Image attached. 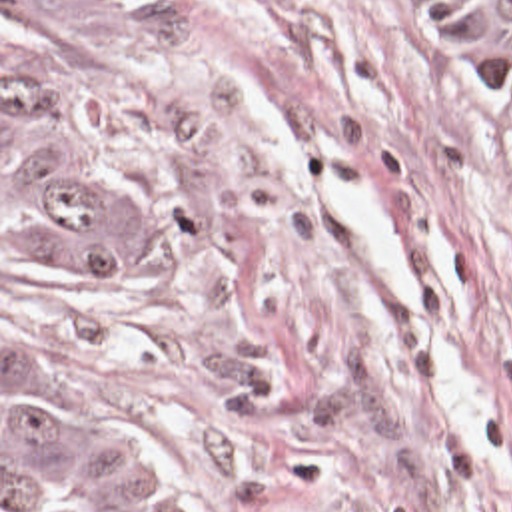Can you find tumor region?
<instances>
[{"mask_svg":"<svg viewBox=\"0 0 512 512\" xmlns=\"http://www.w3.org/2000/svg\"><path fill=\"white\" fill-rule=\"evenodd\" d=\"M512 101V0H453ZM120 0H2V267L54 287H116L136 235L86 139L116 77ZM2 329V496L12 512H208L150 418L70 396Z\"/></svg>","mask_w":512,"mask_h":512,"instance_id":"1","label":"tumor region"}]
</instances>
